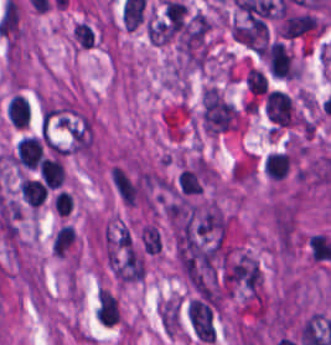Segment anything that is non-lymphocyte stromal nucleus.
I'll return each mask as SVG.
<instances>
[{
  "label": "non-lymphocyte stromal nucleus",
  "mask_w": 331,
  "mask_h": 345,
  "mask_svg": "<svg viewBox=\"0 0 331 345\" xmlns=\"http://www.w3.org/2000/svg\"><path fill=\"white\" fill-rule=\"evenodd\" d=\"M72 35L84 48H91L93 45V32L85 22H77L72 30Z\"/></svg>",
  "instance_id": "non-lymphocyte-stromal-nucleus-7"
},
{
  "label": "non-lymphocyte stromal nucleus",
  "mask_w": 331,
  "mask_h": 345,
  "mask_svg": "<svg viewBox=\"0 0 331 345\" xmlns=\"http://www.w3.org/2000/svg\"><path fill=\"white\" fill-rule=\"evenodd\" d=\"M144 253L156 254L160 249V235L155 225L146 224L139 230Z\"/></svg>",
  "instance_id": "non-lymphocyte-stromal-nucleus-5"
},
{
  "label": "non-lymphocyte stromal nucleus",
  "mask_w": 331,
  "mask_h": 345,
  "mask_svg": "<svg viewBox=\"0 0 331 345\" xmlns=\"http://www.w3.org/2000/svg\"><path fill=\"white\" fill-rule=\"evenodd\" d=\"M74 240L75 230L71 227V225H64L55 235L51 244V251L62 258Z\"/></svg>",
  "instance_id": "non-lymphocyte-stromal-nucleus-4"
},
{
  "label": "non-lymphocyte stromal nucleus",
  "mask_w": 331,
  "mask_h": 345,
  "mask_svg": "<svg viewBox=\"0 0 331 345\" xmlns=\"http://www.w3.org/2000/svg\"><path fill=\"white\" fill-rule=\"evenodd\" d=\"M177 183L179 190L184 194H198L203 188L196 172L189 168H182Z\"/></svg>",
  "instance_id": "non-lymphocyte-stromal-nucleus-6"
},
{
  "label": "non-lymphocyte stromal nucleus",
  "mask_w": 331,
  "mask_h": 345,
  "mask_svg": "<svg viewBox=\"0 0 331 345\" xmlns=\"http://www.w3.org/2000/svg\"><path fill=\"white\" fill-rule=\"evenodd\" d=\"M187 318L195 337L202 342H214L216 336V312L205 295H197L189 301Z\"/></svg>",
  "instance_id": "non-lymphocyte-stromal-nucleus-2"
},
{
  "label": "non-lymphocyte stromal nucleus",
  "mask_w": 331,
  "mask_h": 345,
  "mask_svg": "<svg viewBox=\"0 0 331 345\" xmlns=\"http://www.w3.org/2000/svg\"><path fill=\"white\" fill-rule=\"evenodd\" d=\"M265 113L267 118L279 126H290L294 122L291 96L277 90L267 91Z\"/></svg>",
  "instance_id": "non-lymphocyte-stromal-nucleus-3"
},
{
  "label": "non-lymphocyte stromal nucleus",
  "mask_w": 331,
  "mask_h": 345,
  "mask_svg": "<svg viewBox=\"0 0 331 345\" xmlns=\"http://www.w3.org/2000/svg\"><path fill=\"white\" fill-rule=\"evenodd\" d=\"M219 276L228 289L249 295H257L262 282L257 260L246 254H239L226 262Z\"/></svg>",
  "instance_id": "non-lymphocyte-stromal-nucleus-1"
}]
</instances>
